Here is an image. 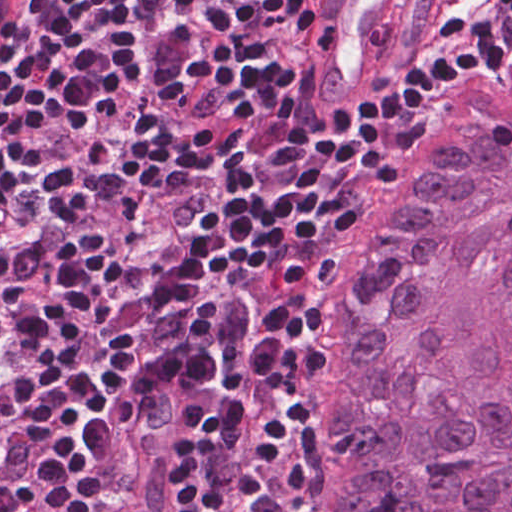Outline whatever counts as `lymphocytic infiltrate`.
I'll return each instance as SVG.
<instances>
[{"label":"lymphocytic infiltrate","mask_w":512,"mask_h":512,"mask_svg":"<svg viewBox=\"0 0 512 512\" xmlns=\"http://www.w3.org/2000/svg\"><path fill=\"white\" fill-rule=\"evenodd\" d=\"M324 0H54L0 64V512H106L126 401L181 390L194 512H298V404L368 183L427 94L512 60L454 0L313 112Z\"/></svg>","instance_id":"lymphocytic-infiltrate-1"}]
</instances>
